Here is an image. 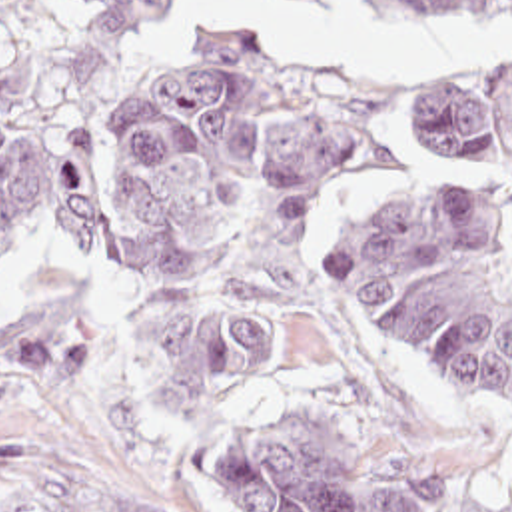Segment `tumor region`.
Listing matches in <instances>:
<instances>
[{
    "label": "tumor region",
    "mask_w": 512,
    "mask_h": 512,
    "mask_svg": "<svg viewBox=\"0 0 512 512\" xmlns=\"http://www.w3.org/2000/svg\"><path fill=\"white\" fill-rule=\"evenodd\" d=\"M97 54H133L183 0H69ZM315 12L331 0H285ZM376 26L498 14L512 0H365ZM59 56L35 0H0V256L45 210L79 258L157 274L145 328L167 410H197L313 366L339 400L289 410L227 444L241 512H498L466 474L388 434L307 324L287 238L341 170L470 152L512 224V60L331 76L253 38L187 42L109 130L55 122ZM35 230V232H37ZM361 320L406 356L512 412V280L488 216L456 204L378 208L353 234ZM0 324L35 382L83 380V332L55 312ZM87 512H153L95 501Z\"/></svg>",
    "instance_id": "tumor-region-1"
}]
</instances>
